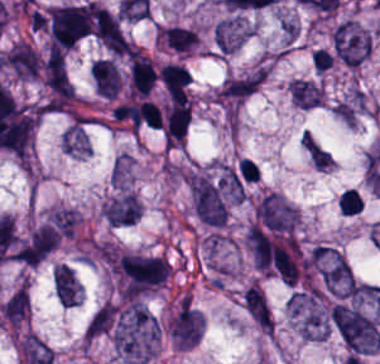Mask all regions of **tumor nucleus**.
Here are the masks:
<instances>
[{
    "instance_id": "21",
    "label": "tumor nucleus",
    "mask_w": 380,
    "mask_h": 364,
    "mask_svg": "<svg viewBox=\"0 0 380 364\" xmlns=\"http://www.w3.org/2000/svg\"><path fill=\"white\" fill-rule=\"evenodd\" d=\"M98 43L111 52H127L120 14Z\"/></svg>"
},
{
    "instance_id": "25",
    "label": "tumor nucleus",
    "mask_w": 380,
    "mask_h": 364,
    "mask_svg": "<svg viewBox=\"0 0 380 364\" xmlns=\"http://www.w3.org/2000/svg\"><path fill=\"white\" fill-rule=\"evenodd\" d=\"M311 58L315 71L319 73L330 67L334 60L324 48H316Z\"/></svg>"
},
{
    "instance_id": "13",
    "label": "tumor nucleus",
    "mask_w": 380,
    "mask_h": 364,
    "mask_svg": "<svg viewBox=\"0 0 380 364\" xmlns=\"http://www.w3.org/2000/svg\"><path fill=\"white\" fill-rule=\"evenodd\" d=\"M191 119V102H171L165 107L162 135L167 144H182Z\"/></svg>"
},
{
    "instance_id": "23",
    "label": "tumor nucleus",
    "mask_w": 380,
    "mask_h": 364,
    "mask_svg": "<svg viewBox=\"0 0 380 364\" xmlns=\"http://www.w3.org/2000/svg\"><path fill=\"white\" fill-rule=\"evenodd\" d=\"M131 159L127 154H119L112 164L109 182L121 186L128 176Z\"/></svg>"
},
{
    "instance_id": "5",
    "label": "tumor nucleus",
    "mask_w": 380,
    "mask_h": 364,
    "mask_svg": "<svg viewBox=\"0 0 380 364\" xmlns=\"http://www.w3.org/2000/svg\"><path fill=\"white\" fill-rule=\"evenodd\" d=\"M90 28L86 10L81 4L51 6L49 33L53 47L71 48Z\"/></svg>"
},
{
    "instance_id": "10",
    "label": "tumor nucleus",
    "mask_w": 380,
    "mask_h": 364,
    "mask_svg": "<svg viewBox=\"0 0 380 364\" xmlns=\"http://www.w3.org/2000/svg\"><path fill=\"white\" fill-rule=\"evenodd\" d=\"M6 67L20 79H35L41 71V54L24 40H17L5 52Z\"/></svg>"
},
{
    "instance_id": "3",
    "label": "tumor nucleus",
    "mask_w": 380,
    "mask_h": 364,
    "mask_svg": "<svg viewBox=\"0 0 380 364\" xmlns=\"http://www.w3.org/2000/svg\"><path fill=\"white\" fill-rule=\"evenodd\" d=\"M330 318L350 355H370L380 348L378 322L361 309L335 302L330 307Z\"/></svg>"
},
{
    "instance_id": "9",
    "label": "tumor nucleus",
    "mask_w": 380,
    "mask_h": 364,
    "mask_svg": "<svg viewBox=\"0 0 380 364\" xmlns=\"http://www.w3.org/2000/svg\"><path fill=\"white\" fill-rule=\"evenodd\" d=\"M200 314L183 298L171 317V342L176 348H192L199 339Z\"/></svg>"
},
{
    "instance_id": "1",
    "label": "tumor nucleus",
    "mask_w": 380,
    "mask_h": 364,
    "mask_svg": "<svg viewBox=\"0 0 380 364\" xmlns=\"http://www.w3.org/2000/svg\"><path fill=\"white\" fill-rule=\"evenodd\" d=\"M158 325L149 310L137 299L117 306L111 342L113 349L131 364H145L156 352Z\"/></svg>"
},
{
    "instance_id": "19",
    "label": "tumor nucleus",
    "mask_w": 380,
    "mask_h": 364,
    "mask_svg": "<svg viewBox=\"0 0 380 364\" xmlns=\"http://www.w3.org/2000/svg\"><path fill=\"white\" fill-rule=\"evenodd\" d=\"M251 317L255 323L268 331L273 330L271 308L266 296L248 285Z\"/></svg>"
},
{
    "instance_id": "24",
    "label": "tumor nucleus",
    "mask_w": 380,
    "mask_h": 364,
    "mask_svg": "<svg viewBox=\"0 0 380 364\" xmlns=\"http://www.w3.org/2000/svg\"><path fill=\"white\" fill-rule=\"evenodd\" d=\"M363 207V198L354 188H347L340 196L339 209L343 213H357Z\"/></svg>"
},
{
    "instance_id": "15",
    "label": "tumor nucleus",
    "mask_w": 380,
    "mask_h": 364,
    "mask_svg": "<svg viewBox=\"0 0 380 364\" xmlns=\"http://www.w3.org/2000/svg\"><path fill=\"white\" fill-rule=\"evenodd\" d=\"M54 286L59 302L65 307H72L79 302L81 284L69 266L61 263L55 266Z\"/></svg>"
},
{
    "instance_id": "18",
    "label": "tumor nucleus",
    "mask_w": 380,
    "mask_h": 364,
    "mask_svg": "<svg viewBox=\"0 0 380 364\" xmlns=\"http://www.w3.org/2000/svg\"><path fill=\"white\" fill-rule=\"evenodd\" d=\"M362 107L363 92L353 88L334 104L333 112L347 125H354Z\"/></svg>"
},
{
    "instance_id": "14",
    "label": "tumor nucleus",
    "mask_w": 380,
    "mask_h": 364,
    "mask_svg": "<svg viewBox=\"0 0 380 364\" xmlns=\"http://www.w3.org/2000/svg\"><path fill=\"white\" fill-rule=\"evenodd\" d=\"M89 74L95 92L113 100L122 83L113 59L97 58L89 68Z\"/></svg>"
},
{
    "instance_id": "20",
    "label": "tumor nucleus",
    "mask_w": 380,
    "mask_h": 364,
    "mask_svg": "<svg viewBox=\"0 0 380 364\" xmlns=\"http://www.w3.org/2000/svg\"><path fill=\"white\" fill-rule=\"evenodd\" d=\"M287 90L290 100L308 110L324 97L315 81L287 88Z\"/></svg>"
},
{
    "instance_id": "16",
    "label": "tumor nucleus",
    "mask_w": 380,
    "mask_h": 364,
    "mask_svg": "<svg viewBox=\"0 0 380 364\" xmlns=\"http://www.w3.org/2000/svg\"><path fill=\"white\" fill-rule=\"evenodd\" d=\"M117 306L113 302H106L90 317L84 332L85 339H94L112 331L116 318Z\"/></svg>"
},
{
    "instance_id": "4",
    "label": "tumor nucleus",
    "mask_w": 380,
    "mask_h": 364,
    "mask_svg": "<svg viewBox=\"0 0 380 364\" xmlns=\"http://www.w3.org/2000/svg\"><path fill=\"white\" fill-rule=\"evenodd\" d=\"M310 258L321 285L328 293L343 298L349 294L355 276L342 253L329 246L315 245Z\"/></svg>"
},
{
    "instance_id": "12",
    "label": "tumor nucleus",
    "mask_w": 380,
    "mask_h": 364,
    "mask_svg": "<svg viewBox=\"0 0 380 364\" xmlns=\"http://www.w3.org/2000/svg\"><path fill=\"white\" fill-rule=\"evenodd\" d=\"M139 200L134 193L118 190L104 202V217L111 226H124L138 218Z\"/></svg>"
},
{
    "instance_id": "17",
    "label": "tumor nucleus",
    "mask_w": 380,
    "mask_h": 364,
    "mask_svg": "<svg viewBox=\"0 0 380 364\" xmlns=\"http://www.w3.org/2000/svg\"><path fill=\"white\" fill-rule=\"evenodd\" d=\"M64 150L75 155H85L90 151L88 131L79 121H74L64 133L61 142Z\"/></svg>"
},
{
    "instance_id": "2",
    "label": "tumor nucleus",
    "mask_w": 380,
    "mask_h": 364,
    "mask_svg": "<svg viewBox=\"0 0 380 364\" xmlns=\"http://www.w3.org/2000/svg\"><path fill=\"white\" fill-rule=\"evenodd\" d=\"M113 270L122 297L136 299L166 280L168 263L155 253L123 249L114 255Z\"/></svg>"
},
{
    "instance_id": "7",
    "label": "tumor nucleus",
    "mask_w": 380,
    "mask_h": 364,
    "mask_svg": "<svg viewBox=\"0 0 380 364\" xmlns=\"http://www.w3.org/2000/svg\"><path fill=\"white\" fill-rule=\"evenodd\" d=\"M60 242V235L47 225H40L17 241V261L35 266L41 263Z\"/></svg>"
},
{
    "instance_id": "6",
    "label": "tumor nucleus",
    "mask_w": 380,
    "mask_h": 364,
    "mask_svg": "<svg viewBox=\"0 0 380 364\" xmlns=\"http://www.w3.org/2000/svg\"><path fill=\"white\" fill-rule=\"evenodd\" d=\"M333 49L345 65H360L372 50L368 32L353 19L339 23L332 33Z\"/></svg>"
},
{
    "instance_id": "11",
    "label": "tumor nucleus",
    "mask_w": 380,
    "mask_h": 364,
    "mask_svg": "<svg viewBox=\"0 0 380 364\" xmlns=\"http://www.w3.org/2000/svg\"><path fill=\"white\" fill-rule=\"evenodd\" d=\"M248 34L242 15L233 14L218 22L213 30V43L218 54H230L242 47Z\"/></svg>"
},
{
    "instance_id": "8",
    "label": "tumor nucleus",
    "mask_w": 380,
    "mask_h": 364,
    "mask_svg": "<svg viewBox=\"0 0 380 364\" xmlns=\"http://www.w3.org/2000/svg\"><path fill=\"white\" fill-rule=\"evenodd\" d=\"M263 76V67H256L228 77L215 96L223 106H237L261 86Z\"/></svg>"
},
{
    "instance_id": "22",
    "label": "tumor nucleus",
    "mask_w": 380,
    "mask_h": 364,
    "mask_svg": "<svg viewBox=\"0 0 380 364\" xmlns=\"http://www.w3.org/2000/svg\"><path fill=\"white\" fill-rule=\"evenodd\" d=\"M139 118L151 127L162 126V115L158 106L152 100H144L137 108Z\"/></svg>"
}]
</instances>
